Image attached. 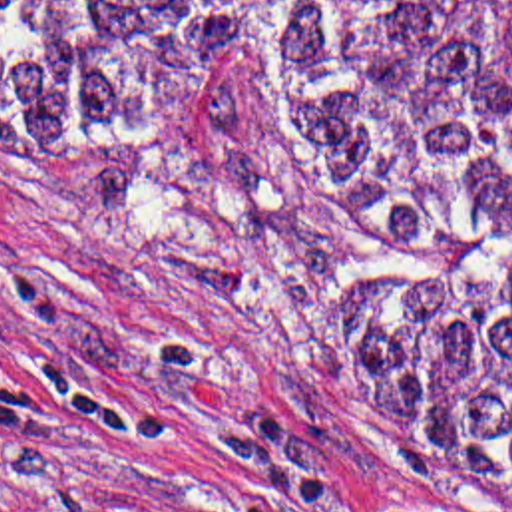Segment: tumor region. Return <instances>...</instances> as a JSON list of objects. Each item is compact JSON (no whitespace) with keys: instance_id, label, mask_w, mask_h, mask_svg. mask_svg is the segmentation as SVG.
<instances>
[{"instance_id":"e687c5a6","label":"tumor region","mask_w":512,"mask_h":512,"mask_svg":"<svg viewBox=\"0 0 512 512\" xmlns=\"http://www.w3.org/2000/svg\"><path fill=\"white\" fill-rule=\"evenodd\" d=\"M261 61L391 248L347 362L377 469L512 507V0H0V119L166 131Z\"/></svg>"}]
</instances>
